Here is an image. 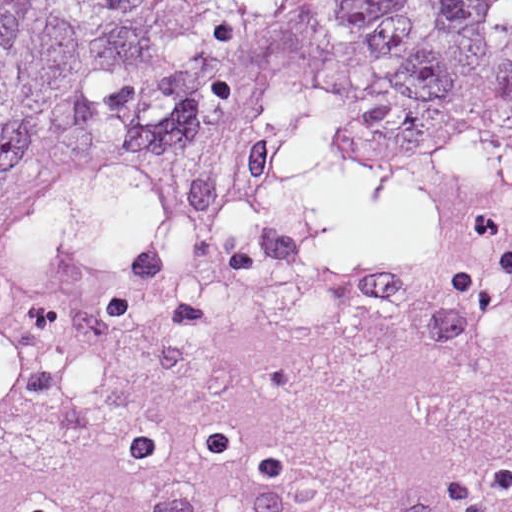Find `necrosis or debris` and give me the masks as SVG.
Returning a JSON list of instances; mask_svg holds the SVG:
<instances>
[{
	"instance_id": "4bbe7bcc",
	"label": "necrosis or debris",
	"mask_w": 512,
	"mask_h": 512,
	"mask_svg": "<svg viewBox=\"0 0 512 512\" xmlns=\"http://www.w3.org/2000/svg\"><path fill=\"white\" fill-rule=\"evenodd\" d=\"M178 217L0 267V512H512V291L409 238Z\"/></svg>"
}]
</instances>
